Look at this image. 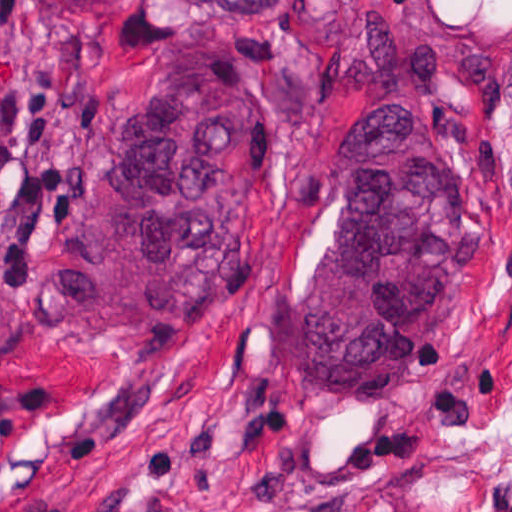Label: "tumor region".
Segmentation results:
<instances>
[{
  "label": "tumor region",
  "mask_w": 512,
  "mask_h": 512,
  "mask_svg": "<svg viewBox=\"0 0 512 512\" xmlns=\"http://www.w3.org/2000/svg\"><path fill=\"white\" fill-rule=\"evenodd\" d=\"M112 11L123 0H48ZM308 60L349 146L338 219L282 318V366L304 402H349L414 372L489 256L468 177L424 150L432 105L492 86L475 45L401 30L398 0H188ZM277 152V98L237 48L161 53L137 112L98 160L56 247L72 311L98 326H183L224 303L246 267L253 187ZM9 239L0 230V346Z\"/></svg>",
  "instance_id": "tumor-region-1"
}]
</instances>
